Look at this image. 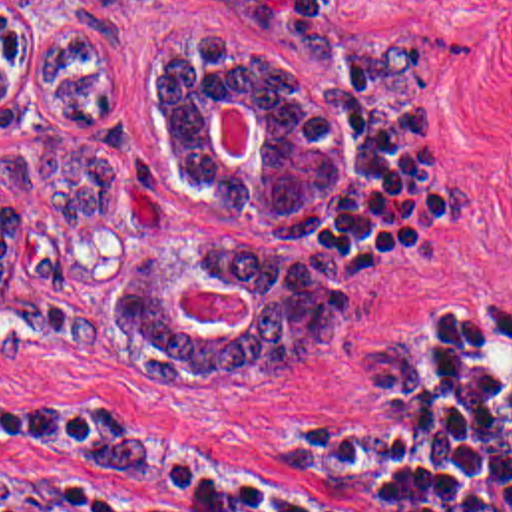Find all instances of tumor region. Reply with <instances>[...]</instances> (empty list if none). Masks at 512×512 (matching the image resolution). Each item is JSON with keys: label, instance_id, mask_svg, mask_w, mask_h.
I'll return each instance as SVG.
<instances>
[{"label": "tumor region", "instance_id": "tumor-region-1", "mask_svg": "<svg viewBox=\"0 0 512 512\" xmlns=\"http://www.w3.org/2000/svg\"><path fill=\"white\" fill-rule=\"evenodd\" d=\"M196 29L166 47L152 121L174 180L258 222L282 240H314L337 206V121L274 57ZM29 63L19 17L0 0V298L11 280L17 202L95 218L110 200V158L61 131H3L15 111L9 83ZM45 103L65 121H99L120 101V63L99 37L65 29L37 67ZM252 109V149L226 160L212 143L216 99ZM246 288L248 324H194L174 308L180 288ZM114 318L132 348L160 364L152 380H202L218 366H264L308 354L341 318V256L312 248L270 256L240 242L170 240L150 248L128 276Z\"/></svg>", "mask_w": 512, "mask_h": 512}]
</instances>
